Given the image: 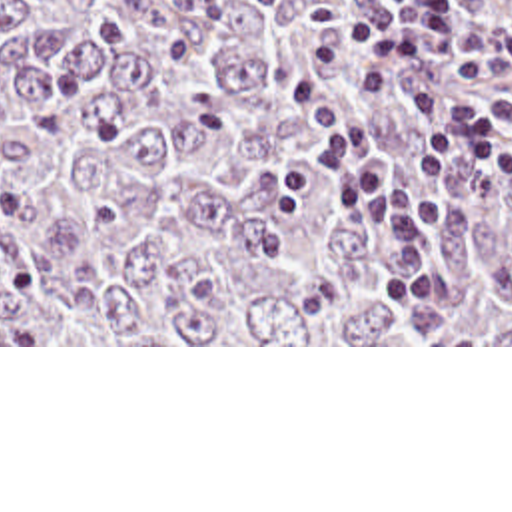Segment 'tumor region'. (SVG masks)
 I'll use <instances>...</instances> for the list:
<instances>
[{
	"mask_svg": "<svg viewBox=\"0 0 512 512\" xmlns=\"http://www.w3.org/2000/svg\"><path fill=\"white\" fill-rule=\"evenodd\" d=\"M386 2L124 6L128 38L94 44L58 0H0V345H512V171L454 159L412 271L302 161L322 141L294 79L404 167L418 91L512 97L424 56L366 97L382 57L340 30L338 71L300 52L312 6ZM450 2L476 30L512 12Z\"/></svg>",
	"mask_w": 512,
	"mask_h": 512,
	"instance_id": "obj_1",
	"label": "tumor region"
}]
</instances>
